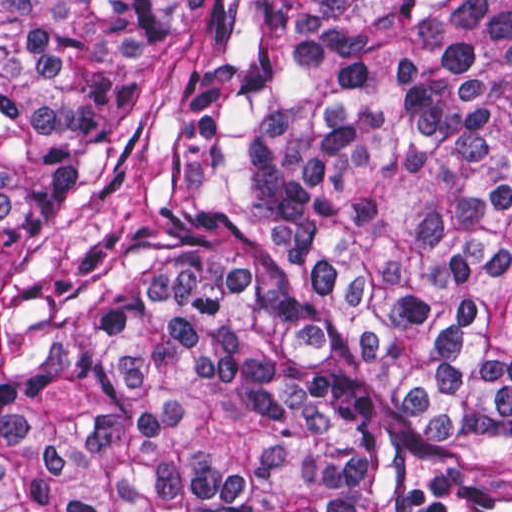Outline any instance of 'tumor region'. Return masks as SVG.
Returning a JSON list of instances; mask_svg holds the SVG:
<instances>
[{"instance_id":"obj_1","label":"tumor region","mask_w":512,"mask_h":512,"mask_svg":"<svg viewBox=\"0 0 512 512\" xmlns=\"http://www.w3.org/2000/svg\"><path fill=\"white\" fill-rule=\"evenodd\" d=\"M0 512H512V0H0Z\"/></svg>"}]
</instances>
